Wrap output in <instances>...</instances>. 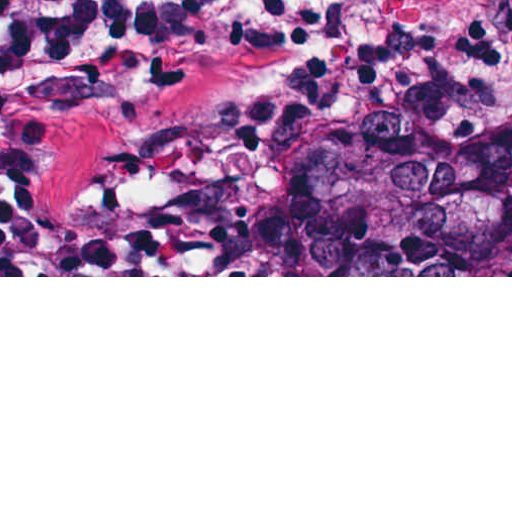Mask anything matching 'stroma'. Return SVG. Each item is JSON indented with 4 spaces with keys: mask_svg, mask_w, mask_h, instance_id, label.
Returning a JSON list of instances; mask_svg holds the SVG:
<instances>
[{
    "mask_svg": "<svg viewBox=\"0 0 512 512\" xmlns=\"http://www.w3.org/2000/svg\"><path fill=\"white\" fill-rule=\"evenodd\" d=\"M386 117L512 142V0H395L363 42L245 47L212 62L174 100V126L316 144ZM0 277H512V271Z\"/></svg>",
    "mask_w": 512,
    "mask_h": 512,
    "instance_id": "35a3bbf8",
    "label": "stroma"
}]
</instances>
